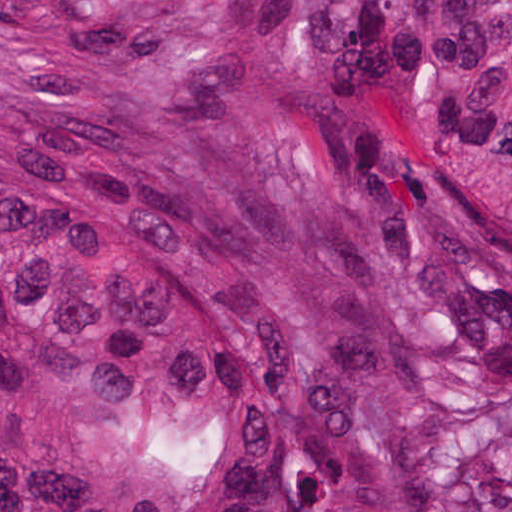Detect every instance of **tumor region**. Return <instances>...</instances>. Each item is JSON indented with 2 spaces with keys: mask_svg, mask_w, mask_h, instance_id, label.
<instances>
[{
  "mask_svg": "<svg viewBox=\"0 0 512 512\" xmlns=\"http://www.w3.org/2000/svg\"><path fill=\"white\" fill-rule=\"evenodd\" d=\"M431 231L512 287V0H1V512H421Z\"/></svg>",
  "mask_w": 512,
  "mask_h": 512,
  "instance_id": "tumor-region-1",
  "label": "tumor region"
}]
</instances>
